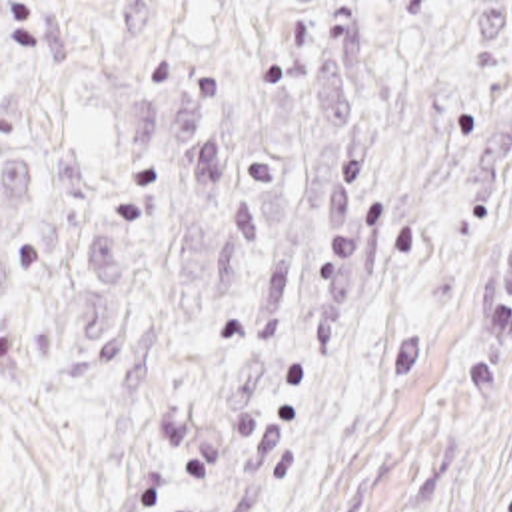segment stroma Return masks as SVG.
Wrapping results in <instances>:
<instances>
[{"label": "stroma", "mask_w": 512, "mask_h": 512, "mask_svg": "<svg viewBox=\"0 0 512 512\" xmlns=\"http://www.w3.org/2000/svg\"><path fill=\"white\" fill-rule=\"evenodd\" d=\"M0 512H512V0H0Z\"/></svg>", "instance_id": "35a3bbf8"}]
</instances>
